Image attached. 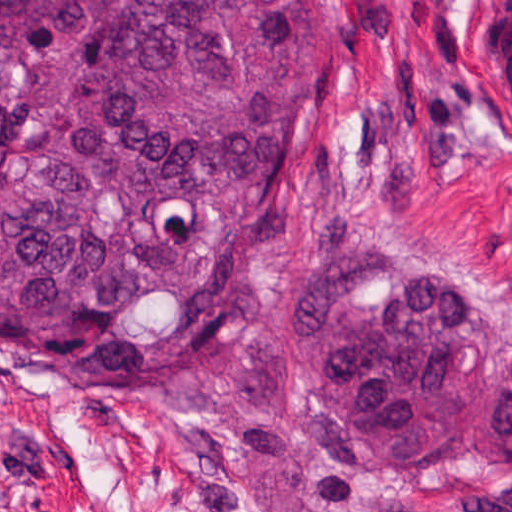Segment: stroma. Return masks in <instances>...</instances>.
Listing matches in <instances>:
<instances>
[{"label": "stroma", "mask_w": 512, "mask_h": 512, "mask_svg": "<svg viewBox=\"0 0 512 512\" xmlns=\"http://www.w3.org/2000/svg\"><path fill=\"white\" fill-rule=\"evenodd\" d=\"M504 0H302L315 58L304 150L218 290L233 344L289 300L312 248L392 223L512 297V123L489 89ZM0 512H512L488 478H342L265 505L192 456L154 405L99 397L0 353Z\"/></svg>", "instance_id": "obj_1"}]
</instances>
